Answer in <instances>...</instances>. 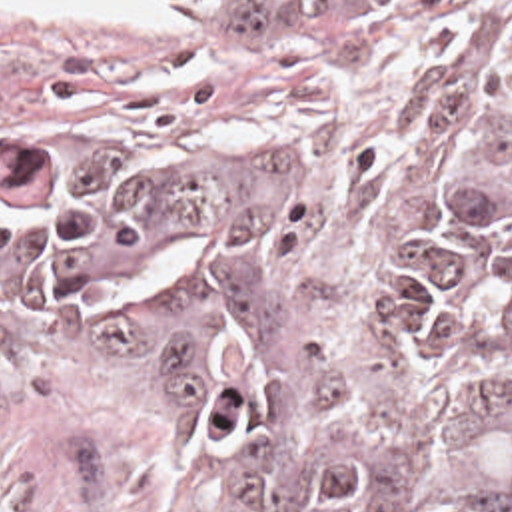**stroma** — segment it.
Listing matches in <instances>:
<instances>
[{"label":"stroma","instance_id":"35a3bbf8","mask_svg":"<svg viewBox=\"0 0 512 512\" xmlns=\"http://www.w3.org/2000/svg\"><path fill=\"white\" fill-rule=\"evenodd\" d=\"M101 24L0 0V182L47 144L206 138L292 198L318 306L368 316L430 192L512 188V0ZM0 512H258L130 372L0 276Z\"/></svg>","mask_w":512,"mask_h":512}]
</instances>
